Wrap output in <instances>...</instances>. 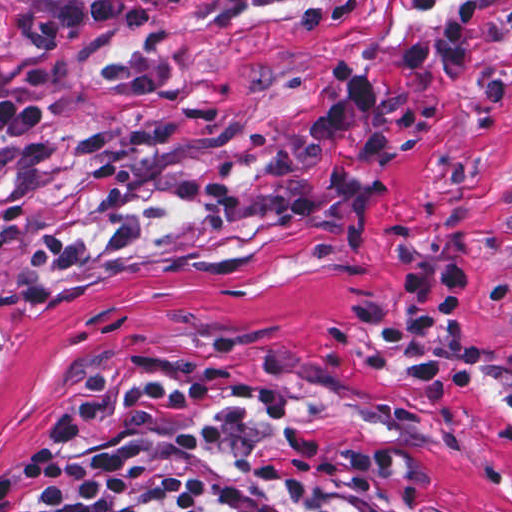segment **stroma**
Wrapping results in <instances>:
<instances>
[{"label": "stroma", "instance_id": "stroma-1", "mask_svg": "<svg viewBox=\"0 0 512 512\" xmlns=\"http://www.w3.org/2000/svg\"><path fill=\"white\" fill-rule=\"evenodd\" d=\"M59 0H0V49ZM163 18L81 37L9 80L54 122L0 137V476L120 362L209 345H270L359 379L395 403L421 495L454 512H512V0H475L476 77L408 74L397 50L449 0H289L229 26L194 0H142ZM333 61L374 72L387 169L344 152L372 183L362 240L275 233L254 216L221 231L166 183L209 171L252 184L291 158L313 201H333L311 113ZM469 261L477 279L445 341L477 351L442 405L407 362L355 328L359 307L404 305L393 245Z\"/></svg>", "mask_w": 512, "mask_h": 512}]
</instances>
